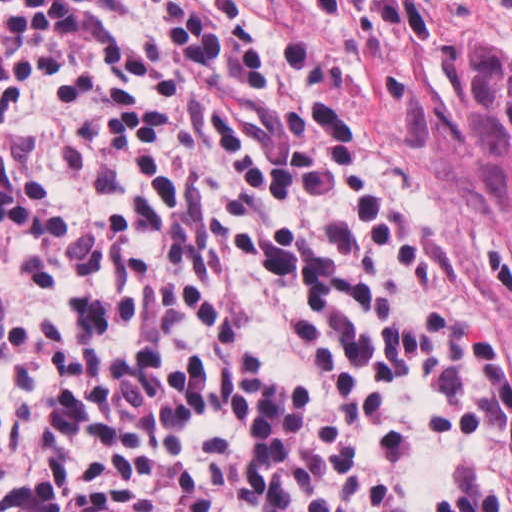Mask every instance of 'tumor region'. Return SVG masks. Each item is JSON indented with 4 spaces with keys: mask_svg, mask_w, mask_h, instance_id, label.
I'll return each mask as SVG.
<instances>
[{
    "mask_svg": "<svg viewBox=\"0 0 512 512\" xmlns=\"http://www.w3.org/2000/svg\"><path fill=\"white\" fill-rule=\"evenodd\" d=\"M455 62L471 195L512 229V59L476 31H455Z\"/></svg>",
    "mask_w": 512,
    "mask_h": 512,
    "instance_id": "e687c5a6",
    "label": "tumor region"
}]
</instances>
